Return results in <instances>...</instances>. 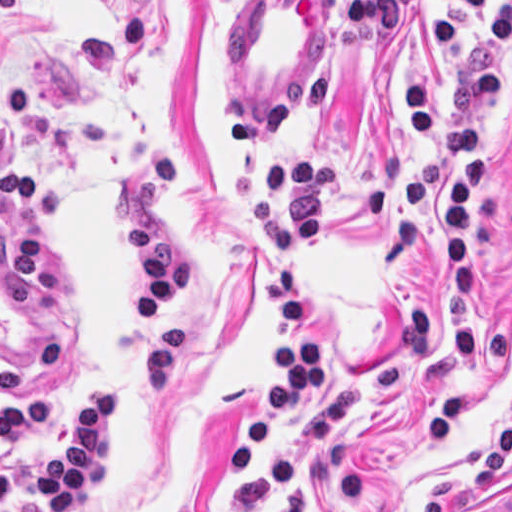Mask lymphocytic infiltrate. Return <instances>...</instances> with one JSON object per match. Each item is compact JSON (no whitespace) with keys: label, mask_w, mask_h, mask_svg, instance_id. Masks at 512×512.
<instances>
[{"label":"lymphocytic infiltrate","mask_w":512,"mask_h":512,"mask_svg":"<svg viewBox=\"0 0 512 512\" xmlns=\"http://www.w3.org/2000/svg\"><path fill=\"white\" fill-rule=\"evenodd\" d=\"M406 0H347L339 25L350 35H389L398 31ZM462 13L480 16L479 34L466 24L444 19L430 29L448 55L478 53L450 75V124L431 88L408 80L406 109L422 140L441 147L415 161L405 174L410 219L418 224L440 180V242L450 268V348L456 362L472 367L478 356L475 314L478 260L473 245L477 204L492 189L488 136L506 91V56L512 46V4L487 11L482 0H444ZM331 73L281 78L257 112L229 105L222 112L224 134L245 149L258 170V193L244 220L276 250L274 266L260 290L272 315L286 326L270 352L280 370L264 397L249 412L248 436L237 449L219 455L215 469L235 485L255 477L270 456L288 444L306 450V465L286 493L259 512H306L314 504L319 478L334 482L339 504L357 497L358 478L345 440L324 450L330 435L358 427L402 389L430 345L426 302L405 309L407 326L396 358L368 371L333 372L328 346L312 333L307 304L298 286V264L326 255V215L342 183L340 160H267L259 146L310 124L329 100ZM34 101L15 84L0 80V123L31 115ZM181 196L176 167L156 146L138 152L128 179L112 189L116 217L126 234L139 275V301L149 326L126 368L93 390L46 437L37 455V488L44 512L87 508L107 498L118 481L116 446L124 418L138 395L161 397L173 390L185 370L182 324L176 304L185 294V254L165 229V214ZM0 204L21 207L23 227L14 239L0 230V275L7 296L21 308L39 299L38 278L48 258L37 240V223L65 219V198L39 184L28 166L0 154ZM287 374V378L285 373ZM48 428L45 400L0 404V451L35 438ZM16 507L15 466L0 464V512ZM421 512H448L446 499H428ZM482 512H512V490Z\"/></svg>","instance_id":"f902f5d3"}]
</instances>
